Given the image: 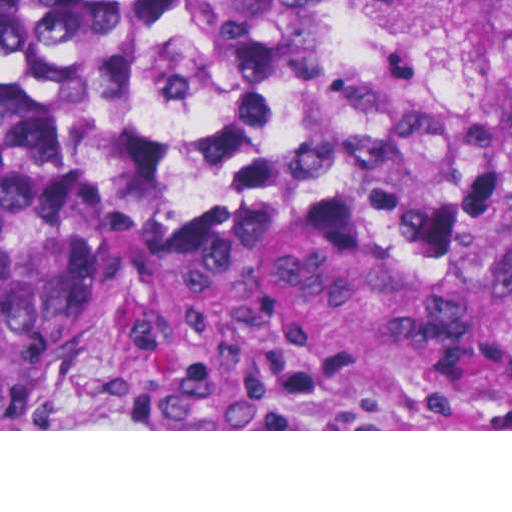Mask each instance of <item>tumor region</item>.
<instances>
[{"label":"tumor region","mask_w":512,"mask_h":512,"mask_svg":"<svg viewBox=\"0 0 512 512\" xmlns=\"http://www.w3.org/2000/svg\"><path fill=\"white\" fill-rule=\"evenodd\" d=\"M382 0H0V429H70L122 245L101 111L193 76L329 61ZM167 382L301 428L379 408L512 411V141L399 195L325 157L209 163L167 235Z\"/></svg>","instance_id":"obj_1"}]
</instances>
